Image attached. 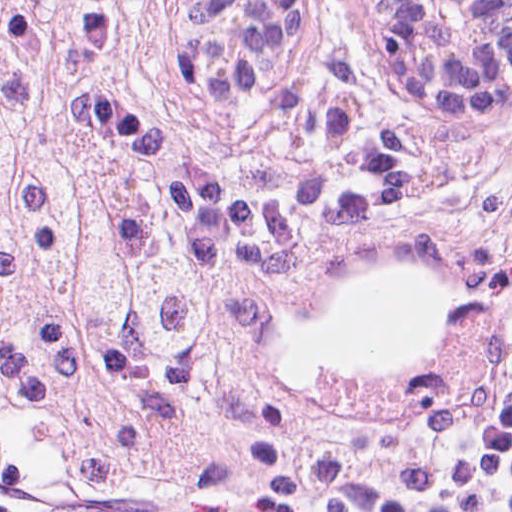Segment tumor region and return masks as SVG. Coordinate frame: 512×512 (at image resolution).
Segmentation results:
<instances>
[{"mask_svg":"<svg viewBox=\"0 0 512 512\" xmlns=\"http://www.w3.org/2000/svg\"><path fill=\"white\" fill-rule=\"evenodd\" d=\"M316 1L291 0L236 112L281 76ZM141 68L145 117L203 168L276 177L255 128L188 102L170 0H0V420L39 425L75 491L157 480L264 394L267 299L201 266L140 171L84 126L83 84Z\"/></svg>","mask_w":512,"mask_h":512,"instance_id":"obj_1","label":"tumor region"}]
</instances>
